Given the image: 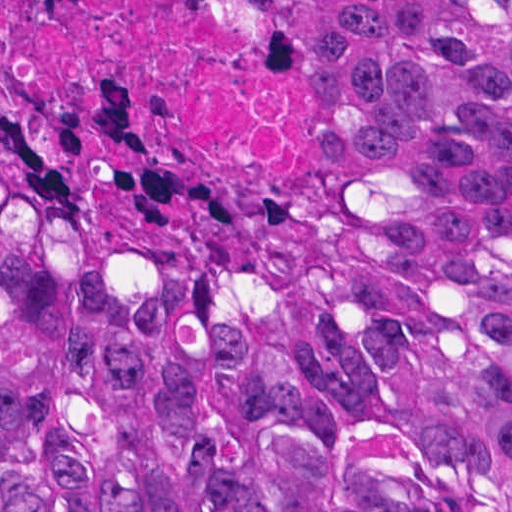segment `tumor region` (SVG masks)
Instances as JSON below:
<instances>
[{"label":"tumor region","mask_w":512,"mask_h":512,"mask_svg":"<svg viewBox=\"0 0 512 512\" xmlns=\"http://www.w3.org/2000/svg\"><path fill=\"white\" fill-rule=\"evenodd\" d=\"M315 4L300 208L0 169V512H512V0Z\"/></svg>","instance_id":"1"}]
</instances>
